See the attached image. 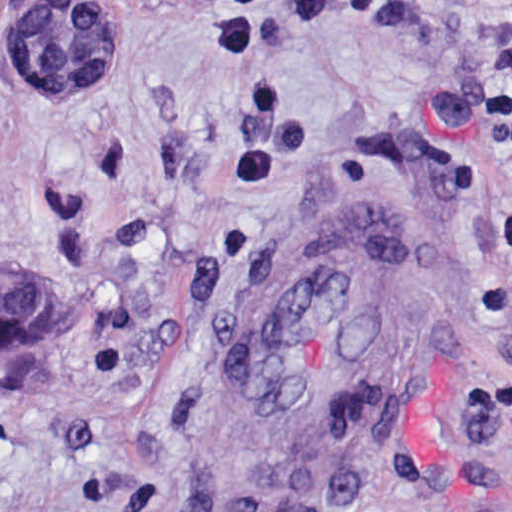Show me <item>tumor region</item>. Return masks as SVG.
Instances as JSON below:
<instances>
[{"mask_svg":"<svg viewBox=\"0 0 512 512\" xmlns=\"http://www.w3.org/2000/svg\"><path fill=\"white\" fill-rule=\"evenodd\" d=\"M132 20L96 0H32L26 18L24 67L29 99H78L101 91L126 65ZM0 291V357L57 319L18 287Z\"/></svg>","mask_w":512,"mask_h":512,"instance_id":"1","label":"tumor region"}]
</instances>
